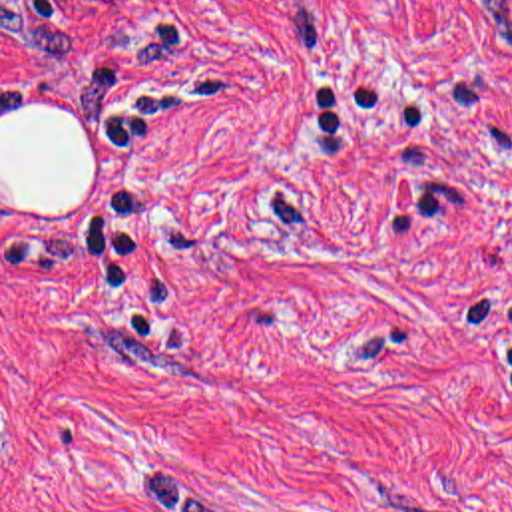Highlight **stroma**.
Instances as JSON below:
<instances>
[{
  "label": "stroma",
  "mask_w": 512,
  "mask_h": 512,
  "mask_svg": "<svg viewBox=\"0 0 512 512\" xmlns=\"http://www.w3.org/2000/svg\"><path fill=\"white\" fill-rule=\"evenodd\" d=\"M0 512H512V0H0Z\"/></svg>",
  "instance_id": "1"
}]
</instances>
